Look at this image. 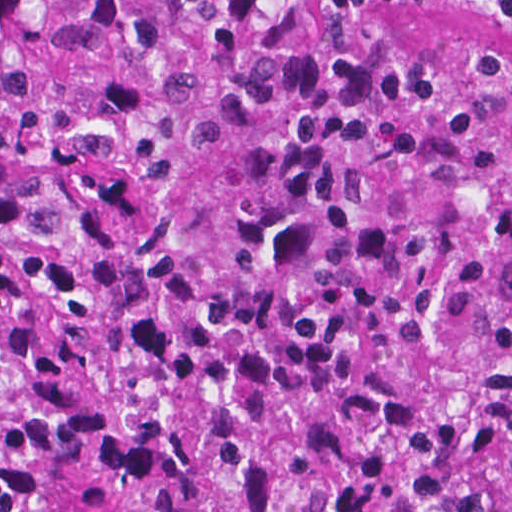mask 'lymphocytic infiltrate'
Returning a JSON list of instances; mask_svg holds the SVG:
<instances>
[{
  "label": "lymphocytic infiltrate",
  "mask_w": 512,
  "mask_h": 512,
  "mask_svg": "<svg viewBox=\"0 0 512 512\" xmlns=\"http://www.w3.org/2000/svg\"><path fill=\"white\" fill-rule=\"evenodd\" d=\"M457 8L482 15H498L512 20V0H447Z\"/></svg>",
  "instance_id": "lymphocytic-infiltrate-1"
}]
</instances>
